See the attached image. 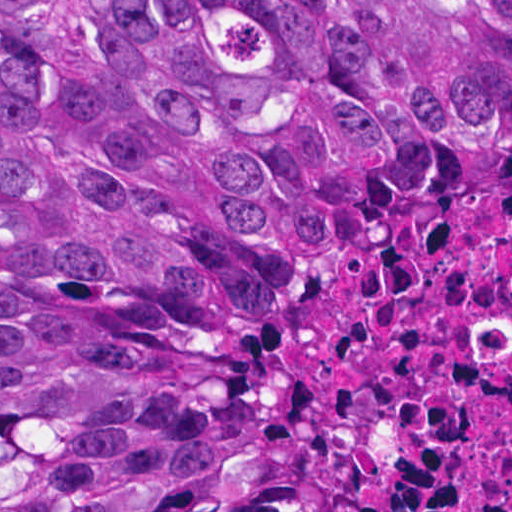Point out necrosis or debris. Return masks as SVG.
Listing matches in <instances>:
<instances>
[{
    "mask_svg": "<svg viewBox=\"0 0 512 512\" xmlns=\"http://www.w3.org/2000/svg\"><path fill=\"white\" fill-rule=\"evenodd\" d=\"M304 319L262 366L377 512H512V186L317 178L275 246Z\"/></svg>",
    "mask_w": 512,
    "mask_h": 512,
    "instance_id": "necrosis-or-debris-1",
    "label": "necrosis or debris"
}]
</instances>
